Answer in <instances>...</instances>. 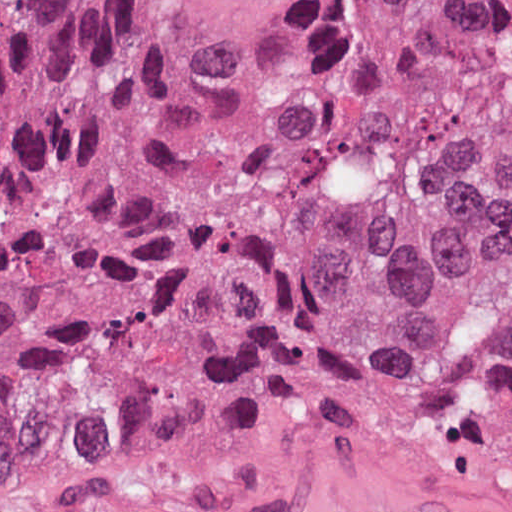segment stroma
Segmentation results:
<instances>
[{
    "label": "stroma",
    "mask_w": 512,
    "mask_h": 512,
    "mask_svg": "<svg viewBox=\"0 0 512 512\" xmlns=\"http://www.w3.org/2000/svg\"><path fill=\"white\" fill-rule=\"evenodd\" d=\"M0 512H512V493L406 412L308 404L103 432L0 483Z\"/></svg>",
    "instance_id": "35a3bbf8"
}]
</instances>
